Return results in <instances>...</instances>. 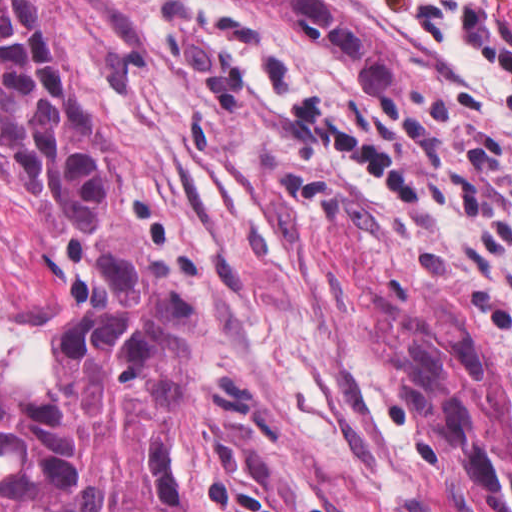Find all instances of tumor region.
Returning <instances> with one entry per match:
<instances>
[{"label":"tumor region","instance_id":"obj_1","mask_svg":"<svg viewBox=\"0 0 512 512\" xmlns=\"http://www.w3.org/2000/svg\"><path fill=\"white\" fill-rule=\"evenodd\" d=\"M224 1L295 21L371 92L412 86L400 49L324 0ZM203 336L33 0H0V506L184 512L178 437ZM397 400L455 488L512 512V389L492 323L423 288Z\"/></svg>","mask_w":512,"mask_h":512}]
</instances>
